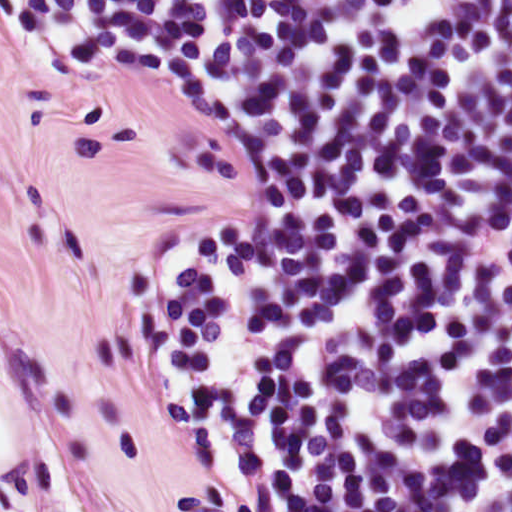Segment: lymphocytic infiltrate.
<instances>
[{"instance_id":"lymphocytic-infiltrate-1","label":"lymphocytic infiltrate","mask_w":512,"mask_h":512,"mask_svg":"<svg viewBox=\"0 0 512 512\" xmlns=\"http://www.w3.org/2000/svg\"><path fill=\"white\" fill-rule=\"evenodd\" d=\"M0 38L241 121L139 306L226 512H512V0H0Z\"/></svg>"}]
</instances>
